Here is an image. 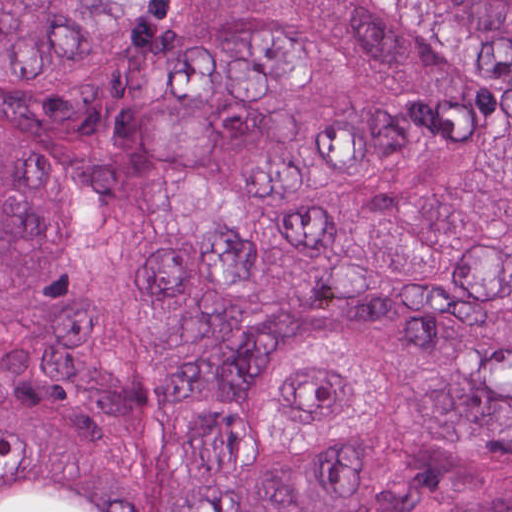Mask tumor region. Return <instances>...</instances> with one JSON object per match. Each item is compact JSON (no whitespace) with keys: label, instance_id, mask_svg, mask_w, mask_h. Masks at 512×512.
I'll use <instances>...</instances> for the list:
<instances>
[{"label":"tumor region","instance_id":"tumor-region-1","mask_svg":"<svg viewBox=\"0 0 512 512\" xmlns=\"http://www.w3.org/2000/svg\"><path fill=\"white\" fill-rule=\"evenodd\" d=\"M0 512H512V0H0Z\"/></svg>","mask_w":512,"mask_h":512}]
</instances>
